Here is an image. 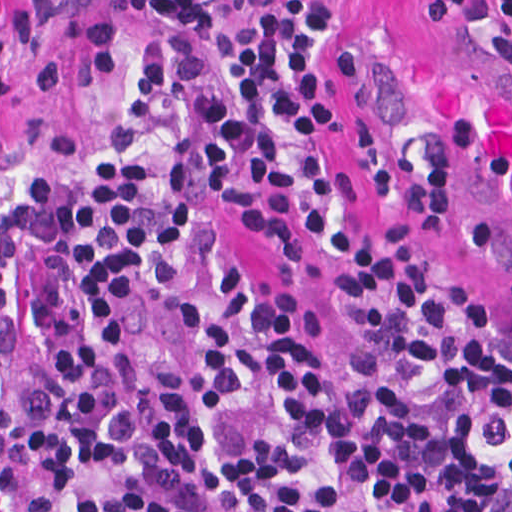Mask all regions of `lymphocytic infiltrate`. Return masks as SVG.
Masks as SVG:
<instances>
[{
  "mask_svg": "<svg viewBox=\"0 0 512 512\" xmlns=\"http://www.w3.org/2000/svg\"><path fill=\"white\" fill-rule=\"evenodd\" d=\"M429 26L512 0H424ZM329 0H135L110 101L1 188V512H512V318L341 234L331 381L218 212L294 262L328 216Z\"/></svg>",
  "mask_w": 512,
  "mask_h": 512,
  "instance_id": "lymphocytic-infiltrate-1",
  "label": "lymphocytic infiltrate"
}]
</instances>
